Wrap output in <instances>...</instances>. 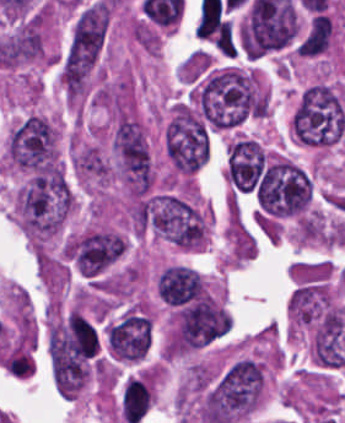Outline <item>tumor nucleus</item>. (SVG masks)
<instances>
[{"label": "tumor nucleus", "instance_id": "6", "mask_svg": "<svg viewBox=\"0 0 345 423\" xmlns=\"http://www.w3.org/2000/svg\"><path fill=\"white\" fill-rule=\"evenodd\" d=\"M292 139L302 146L328 147L345 134V105L338 90L316 81L300 92L289 120Z\"/></svg>", "mask_w": 345, "mask_h": 423}, {"label": "tumor nucleus", "instance_id": "13", "mask_svg": "<svg viewBox=\"0 0 345 423\" xmlns=\"http://www.w3.org/2000/svg\"><path fill=\"white\" fill-rule=\"evenodd\" d=\"M157 297L165 300H202L205 296L200 275L188 265L172 264L156 278Z\"/></svg>", "mask_w": 345, "mask_h": 423}, {"label": "tumor nucleus", "instance_id": "11", "mask_svg": "<svg viewBox=\"0 0 345 423\" xmlns=\"http://www.w3.org/2000/svg\"><path fill=\"white\" fill-rule=\"evenodd\" d=\"M335 306L328 283L301 280L287 300L290 320L297 324H322Z\"/></svg>", "mask_w": 345, "mask_h": 423}, {"label": "tumor nucleus", "instance_id": "1", "mask_svg": "<svg viewBox=\"0 0 345 423\" xmlns=\"http://www.w3.org/2000/svg\"><path fill=\"white\" fill-rule=\"evenodd\" d=\"M265 386L263 362L239 357L202 389L198 417L205 423H236L260 403Z\"/></svg>", "mask_w": 345, "mask_h": 423}, {"label": "tumor nucleus", "instance_id": "5", "mask_svg": "<svg viewBox=\"0 0 345 423\" xmlns=\"http://www.w3.org/2000/svg\"><path fill=\"white\" fill-rule=\"evenodd\" d=\"M150 231L179 249H199L206 241L204 210L189 190H158L141 200Z\"/></svg>", "mask_w": 345, "mask_h": 423}, {"label": "tumor nucleus", "instance_id": "3", "mask_svg": "<svg viewBox=\"0 0 345 423\" xmlns=\"http://www.w3.org/2000/svg\"><path fill=\"white\" fill-rule=\"evenodd\" d=\"M108 22V3L90 0L74 15L58 64L61 88L69 96L85 93Z\"/></svg>", "mask_w": 345, "mask_h": 423}, {"label": "tumor nucleus", "instance_id": "2", "mask_svg": "<svg viewBox=\"0 0 345 423\" xmlns=\"http://www.w3.org/2000/svg\"><path fill=\"white\" fill-rule=\"evenodd\" d=\"M73 204V191L61 170L45 168L15 192V212L31 241L44 242L60 232Z\"/></svg>", "mask_w": 345, "mask_h": 423}, {"label": "tumor nucleus", "instance_id": "7", "mask_svg": "<svg viewBox=\"0 0 345 423\" xmlns=\"http://www.w3.org/2000/svg\"><path fill=\"white\" fill-rule=\"evenodd\" d=\"M311 192V182L303 168L282 156L264 167L255 189L257 204L278 216L302 211Z\"/></svg>", "mask_w": 345, "mask_h": 423}, {"label": "tumor nucleus", "instance_id": "12", "mask_svg": "<svg viewBox=\"0 0 345 423\" xmlns=\"http://www.w3.org/2000/svg\"><path fill=\"white\" fill-rule=\"evenodd\" d=\"M264 164L260 144L250 138L237 137L227 146L224 174L232 189H252Z\"/></svg>", "mask_w": 345, "mask_h": 423}, {"label": "tumor nucleus", "instance_id": "4", "mask_svg": "<svg viewBox=\"0 0 345 423\" xmlns=\"http://www.w3.org/2000/svg\"><path fill=\"white\" fill-rule=\"evenodd\" d=\"M205 120L227 129L260 113L259 75L227 68L210 74L195 93Z\"/></svg>", "mask_w": 345, "mask_h": 423}, {"label": "tumor nucleus", "instance_id": "8", "mask_svg": "<svg viewBox=\"0 0 345 423\" xmlns=\"http://www.w3.org/2000/svg\"><path fill=\"white\" fill-rule=\"evenodd\" d=\"M111 156L115 179L131 196H143L152 186V166L146 133L136 122H117L112 130Z\"/></svg>", "mask_w": 345, "mask_h": 423}, {"label": "tumor nucleus", "instance_id": "9", "mask_svg": "<svg viewBox=\"0 0 345 423\" xmlns=\"http://www.w3.org/2000/svg\"><path fill=\"white\" fill-rule=\"evenodd\" d=\"M165 145L172 168L181 172H193L209 153L201 119L182 102L173 104L165 127Z\"/></svg>", "mask_w": 345, "mask_h": 423}, {"label": "tumor nucleus", "instance_id": "10", "mask_svg": "<svg viewBox=\"0 0 345 423\" xmlns=\"http://www.w3.org/2000/svg\"><path fill=\"white\" fill-rule=\"evenodd\" d=\"M107 347L112 357L137 361L147 351L150 318L123 313L104 328Z\"/></svg>", "mask_w": 345, "mask_h": 423}]
</instances>
